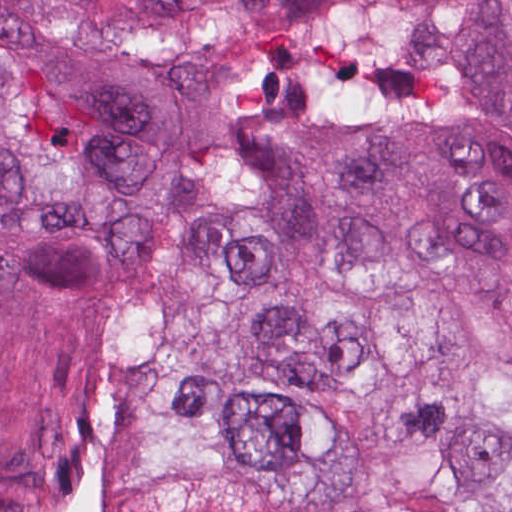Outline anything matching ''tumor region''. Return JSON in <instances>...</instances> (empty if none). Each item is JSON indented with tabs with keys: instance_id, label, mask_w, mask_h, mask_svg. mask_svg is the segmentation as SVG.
Here are the masks:
<instances>
[{
	"instance_id": "e687c5a6",
	"label": "tumor region",
	"mask_w": 512,
	"mask_h": 512,
	"mask_svg": "<svg viewBox=\"0 0 512 512\" xmlns=\"http://www.w3.org/2000/svg\"><path fill=\"white\" fill-rule=\"evenodd\" d=\"M0 512H512V0H0ZM138 283L72 222L160 241Z\"/></svg>"
}]
</instances>
